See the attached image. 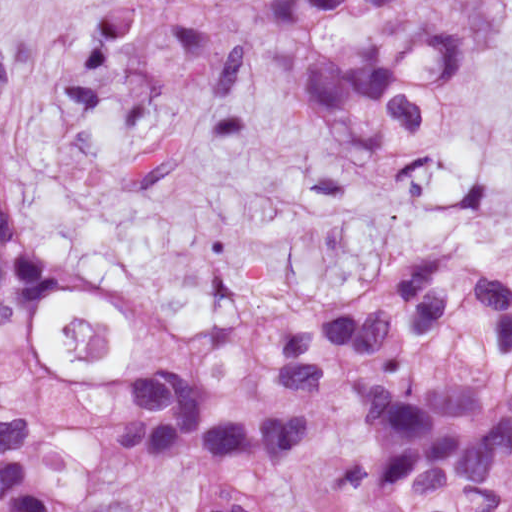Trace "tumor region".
Wrapping results in <instances>:
<instances>
[{
	"instance_id": "1",
	"label": "tumor region",
	"mask_w": 512,
	"mask_h": 512,
	"mask_svg": "<svg viewBox=\"0 0 512 512\" xmlns=\"http://www.w3.org/2000/svg\"><path fill=\"white\" fill-rule=\"evenodd\" d=\"M354 1L263 0L262 30L341 137L396 154L454 47L429 19L378 67L332 51ZM11 120L0 84V512H56L126 466L148 471L131 512H512V269L450 245L328 306L166 318L79 391L40 331L77 283L2 205Z\"/></svg>"
}]
</instances>
